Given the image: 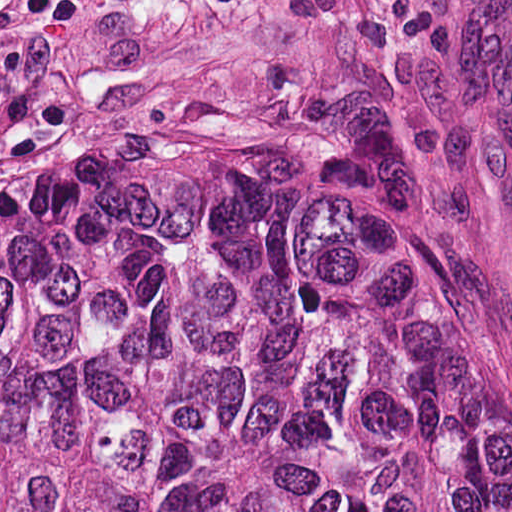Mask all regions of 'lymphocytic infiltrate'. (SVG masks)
Returning a JSON list of instances; mask_svg holds the SVG:
<instances>
[{
  "mask_svg": "<svg viewBox=\"0 0 512 512\" xmlns=\"http://www.w3.org/2000/svg\"><path fill=\"white\" fill-rule=\"evenodd\" d=\"M23 16L37 23H67L75 18V0H18Z\"/></svg>",
  "mask_w": 512,
  "mask_h": 512,
  "instance_id": "1",
  "label": "lymphocytic infiltrate"
}]
</instances>
